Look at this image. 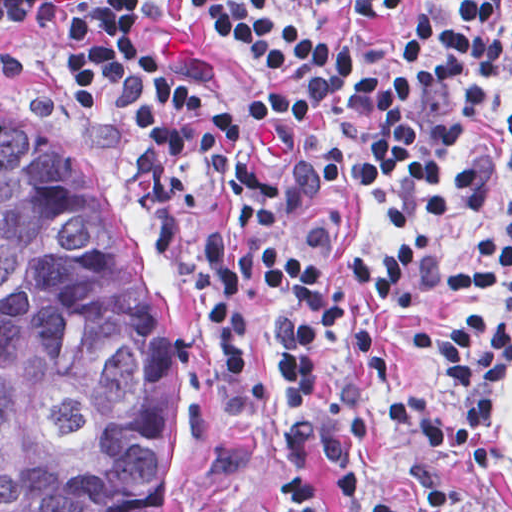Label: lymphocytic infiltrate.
<instances>
[{"label": "lymphocytic infiltrate", "mask_w": 512, "mask_h": 512, "mask_svg": "<svg viewBox=\"0 0 512 512\" xmlns=\"http://www.w3.org/2000/svg\"><path fill=\"white\" fill-rule=\"evenodd\" d=\"M0 21L60 27V69L120 121L159 204L170 265L248 422L267 405L249 367L259 295L301 465L311 388L336 328L346 387L327 408L331 457L370 430L374 399L394 430L444 463H490V407L512 357V213L461 261L436 260L423 238L346 265L398 307L448 286L496 292L491 309L459 311L410 340L446 367L440 391L400 384L341 295L277 229L314 200L345 196L424 226L502 187L512 113L491 92L512 57V23L498 1H0ZM254 512L339 510L313 482L282 479ZM378 512L418 511L398 494Z\"/></svg>", "instance_id": "1"}]
</instances>
